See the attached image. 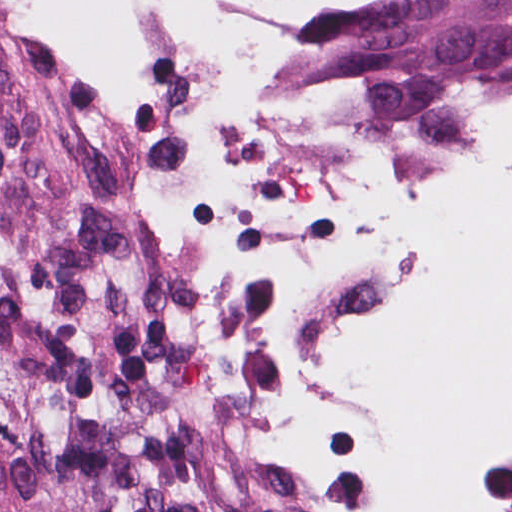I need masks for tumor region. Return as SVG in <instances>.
Returning <instances> with one entry per match:
<instances>
[{
	"mask_svg": "<svg viewBox=\"0 0 512 512\" xmlns=\"http://www.w3.org/2000/svg\"><path fill=\"white\" fill-rule=\"evenodd\" d=\"M512 54V0H335L255 71ZM0 44V512H286L263 387L176 282L68 201Z\"/></svg>",
	"mask_w": 512,
	"mask_h": 512,
	"instance_id": "e687c5a6",
	"label": "tumor region"
}]
</instances>
